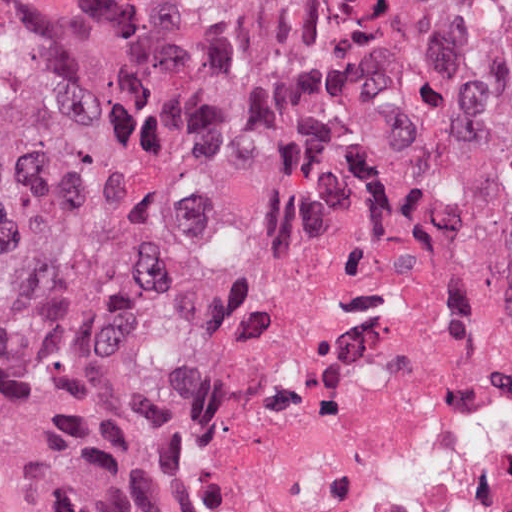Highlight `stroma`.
Masks as SVG:
<instances>
[{"label":"stroma","mask_w":512,"mask_h":512,"mask_svg":"<svg viewBox=\"0 0 512 512\" xmlns=\"http://www.w3.org/2000/svg\"><path fill=\"white\" fill-rule=\"evenodd\" d=\"M312 201H381L421 211L463 234L488 265L496 295L512 323V286L477 248L459 222L428 211L374 198H322ZM312 201L282 209L238 236L178 261L151 276L139 301L124 316L120 334V406L123 421L136 439L151 477L160 512H197L185 490L172 447L164 406L153 374V351L159 332L191 301L211 268L228 252ZM0 512H18L0 494Z\"/></svg>","instance_id":"stroma-1"}]
</instances>
